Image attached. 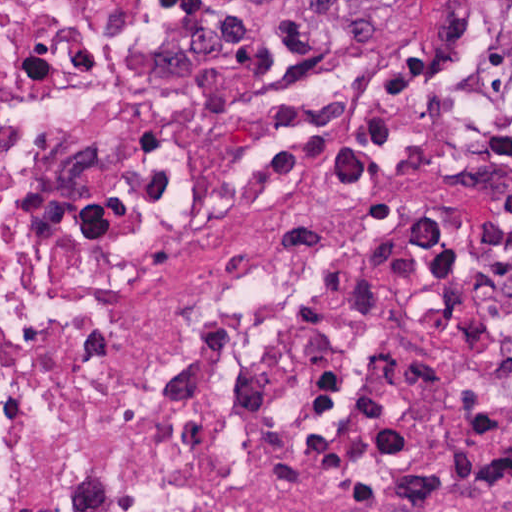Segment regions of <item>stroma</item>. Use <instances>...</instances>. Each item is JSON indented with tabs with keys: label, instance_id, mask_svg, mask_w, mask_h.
Returning a JSON list of instances; mask_svg holds the SVG:
<instances>
[{
	"label": "stroma",
	"instance_id": "35a3bbf8",
	"mask_svg": "<svg viewBox=\"0 0 512 512\" xmlns=\"http://www.w3.org/2000/svg\"><path fill=\"white\" fill-rule=\"evenodd\" d=\"M140 14L183 56L351 93L358 176L336 276L415 343L450 423L512 496V0H68Z\"/></svg>",
	"mask_w": 512,
	"mask_h": 512
}]
</instances>
